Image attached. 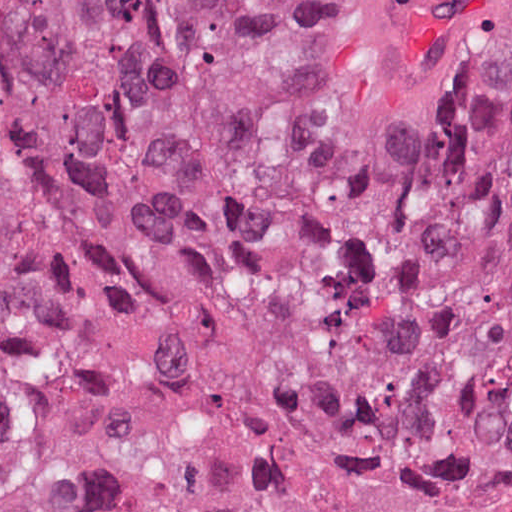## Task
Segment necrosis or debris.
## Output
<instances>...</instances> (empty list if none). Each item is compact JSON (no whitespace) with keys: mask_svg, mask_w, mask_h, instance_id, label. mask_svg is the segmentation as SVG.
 Returning a JSON list of instances; mask_svg holds the SVG:
<instances>
[{"mask_svg":"<svg viewBox=\"0 0 512 512\" xmlns=\"http://www.w3.org/2000/svg\"><path fill=\"white\" fill-rule=\"evenodd\" d=\"M413 201L322 135L287 131L236 280L200 331L121 343L0 299V358L75 385L103 512H512V488L381 442L338 392L351 259Z\"/></svg>","mask_w":512,"mask_h":512,"instance_id":"obj_1","label":"necrosis or debris"}]
</instances>
